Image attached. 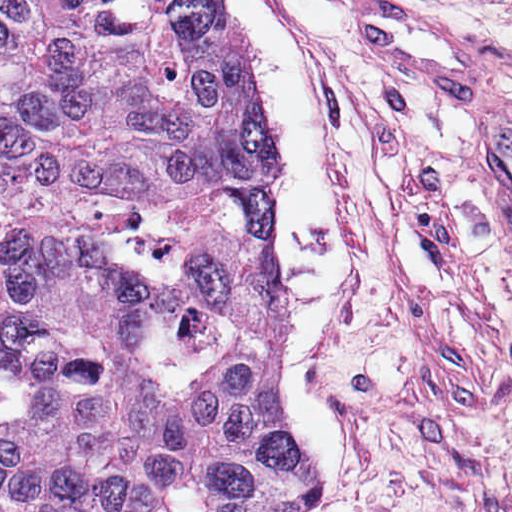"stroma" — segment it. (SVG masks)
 I'll list each match as a JSON object with an SVG mask.
<instances>
[{"mask_svg": "<svg viewBox=\"0 0 512 512\" xmlns=\"http://www.w3.org/2000/svg\"><path fill=\"white\" fill-rule=\"evenodd\" d=\"M272 1L323 91L350 199L327 337L352 451L334 512H512V248L460 154L469 98L350 23L424 6L480 49L478 98H512V0Z\"/></svg>", "mask_w": 512, "mask_h": 512, "instance_id": "35a3bbf8", "label": "stroma"}]
</instances>
